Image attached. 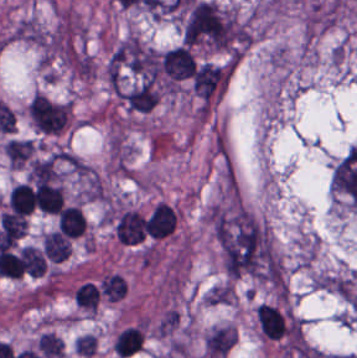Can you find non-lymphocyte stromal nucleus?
<instances>
[{
    "label": "non-lymphocyte stromal nucleus",
    "mask_w": 357,
    "mask_h": 358,
    "mask_svg": "<svg viewBox=\"0 0 357 358\" xmlns=\"http://www.w3.org/2000/svg\"><path fill=\"white\" fill-rule=\"evenodd\" d=\"M183 33L189 43L229 46L234 15L216 1L198 0L186 18Z\"/></svg>",
    "instance_id": "non-lymphocyte-stromal-nucleus-1"
},
{
    "label": "non-lymphocyte stromal nucleus",
    "mask_w": 357,
    "mask_h": 358,
    "mask_svg": "<svg viewBox=\"0 0 357 358\" xmlns=\"http://www.w3.org/2000/svg\"><path fill=\"white\" fill-rule=\"evenodd\" d=\"M27 114L35 131L59 134L69 125L71 105L44 92H36L27 105Z\"/></svg>",
    "instance_id": "non-lymphocyte-stromal-nucleus-2"
},
{
    "label": "non-lymphocyte stromal nucleus",
    "mask_w": 357,
    "mask_h": 358,
    "mask_svg": "<svg viewBox=\"0 0 357 358\" xmlns=\"http://www.w3.org/2000/svg\"><path fill=\"white\" fill-rule=\"evenodd\" d=\"M236 342L234 324H220L211 328L204 336L205 356L221 358L230 352Z\"/></svg>",
    "instance_id": "non-lymphocyte-stromal-nucleus-3"
},
{
    "label": "non-lymphocyte stromal nucleus",
    "mask_w": 357,
    "mask_h": 358,
    "mask_svg": "<svg viewBox=\"0 0 357 358\" xmlns=\"http://www.w3.org/2000/svg\"><path fill=\"white\" fill-rule=\"evenodd\" d=\"M35 149L29 139H9L6 141L3 151L13 167H20Z\"/></svg>",
    "instance_id": "non-lymphocyte-stromal-nucleus-4"
},
{
    "label": "non-lymphocyte stromal nucleus",
    "mask_w": 357,
    "mask_h": 358,
    "mask_svg": "<svg viewBox=\"0 0 357 358\" xmlns=\"http://www.w3.org/2000/svg\"><path fill=\"white\" fill-rule=\"evenodd\" d=\"M235 300V292L231 283L223 282L214 285L208 291L204 302L208 304H230Z\"/></svg>",
    "instance_id": "non-lymphocyte-stromal-nucleus-5"
}]
</instances>
